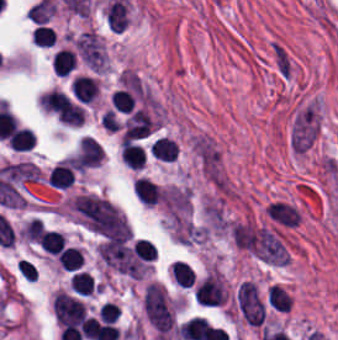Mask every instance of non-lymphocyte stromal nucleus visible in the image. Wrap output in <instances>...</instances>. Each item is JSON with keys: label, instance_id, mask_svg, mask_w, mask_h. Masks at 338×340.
Listing matches in <instances>:
<instances>
[{"label": "non-lymphocyte stromal nucleus", "instance_id": "non-lymphocyte-stromal-nucleus-1", "mask_svg": "<svg viewBox=\"0 0 338 340\" xmlns=\"http://www.w3.org/2000/svg\"><path fill=\"white\" fill-rule=\"evenodd\" d=\"M76 220L95 234L130 238L131 227L114 203L104 196L82 193L71 203Z\"/></svg>", "mask_w": 338, "mask_h": 340}, {"label": "non-lymphocyte stromal nucleus", "instance_id": "non-lymphocyte-stromal-nucleus-2", "mask_svg": "<svg viewBox=\"0 0 338 340\" xmlns=\"http://www.w3.org/2000/svg\"><path fill=\"white\" fill-rule=\"evenodd\" d=\"M160 203L174 239H189L191 229V198L180 185L161 188Z\"/></svg>", "mask_w": 338, "mask_h": 340}, {"label": "non-lymphocyte stromal nucleus", "instance_id": "non-lymphocyte-stromal-nucleus-3", "mask_svg": "<svg viewBox=\"0 0 338 340\" xmlns=\"http://www.w3.org/2000/svg\"><path fill=\"white\" fill-rule=\"evenodd\" d=\"M142 310L152 327L168 332L174 323L172 305L165 289L156 283H148L142 298Z\"/></svg>", "mask_w": 338, "mask_h": 340}, {"label": "non-lymphocyte stromal nucleus", "instance_id": "non-lymphocyte-stromal-nucleus-4", "mask_svg": "<svg viewBox=\"0 0 338 340\" xmlns=\"http://www.w3.org/2000/svg\"><path fill=\"white\" fill-rule=\"evenodd\" d=\"M318 126L317 108L303 105L292 120L289 144L293 152H305L312 144Z\"/></svg>", "mask_w": 338, "mask_h": 340}, {"label": "non-lymphocyte stromal nucleus", "instance_id": "non-lymphocyte-stromal-nucleus-5", "mask_svg": "<svg viewBox=\"0 0 338 340\" xmlns=\"http://www.w3.org/2000/svg\"><path fill=\"white\" fill-rule=\"evenodd\" d=\"M237 308L243 321L259 326L264 318V302L256 283L243 280L236 291Z\"/></svg>", "mask_w": 338, "mask_h": 340}, {"label": "non-lymphocyte stromal nucleus", "instance_id": "non-lymphocyte-stromal-nucleus-6", "mask_svg": "<svg viewBox=\"0 0 338 340\" xmlns=\"http://www.w3.org/2000/svg\"><path fill=\"white\" fill-rule=\"evenodd\" d=\"M73 42L83 62L93 72L100 73L106 65V54L96 32L87 30Z\"/></svg>", "mask_w": 338, "mask_h": 340}, {"label": "non-lymphocyte stromal nucleus", "instance_id": "non-lymphocyte-stromal-nucleus-7", "mask_svg": "<svg viewBox=\"0 0 338 340\" xmlns=\"http://www.w3.org/2000/svg\"><path fill=\"white\" fill-rule=\"evenodd\" d=\"M268 50L277 75L285 79L289 78L293 63L284 44L279 40H272Z\"/></svg>", "mask_w": 338, "mask_h": 340}]
</instances>
